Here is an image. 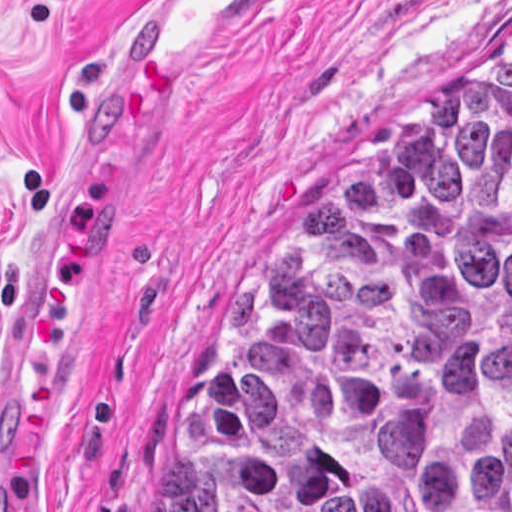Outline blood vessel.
Instances as JSON below:
<instances>
[{"instance_id": "1", "label": "blood vessel", "mask_w": 512, "mask_h": 512, "mask_svg": "<svg viewBox=\"0 0 512 512\" xmlns=\"http://www.w3.org/2000/svg\"><path fill=\"white\" fill-rule=\"evenodd\" d=\"M308 0H134L24 169L54 171L161 135L212 96Z\"/></svg>"}]
</instances>
